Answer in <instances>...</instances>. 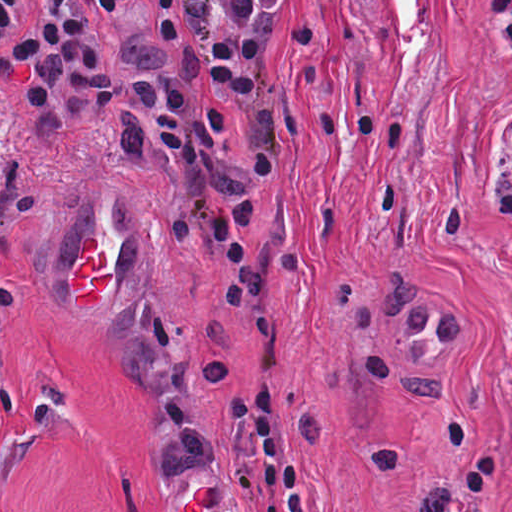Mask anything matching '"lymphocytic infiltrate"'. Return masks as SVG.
<instances>
[{
  "label": "lymphocytic infiltrate",
  "instance_id": "f902f5d3",
  "mask_svg": "<svg viewBox=\"0 0 512 512\" xmlns=\"http://www.w3.org/2000/svg\"><path fill=\"white\" fill-rule=\"evenodd\" d=\"M17 3L0 0V39ZM43 4L34 35L0 59V91L23 90L42 140L114 127L130 161L164 175L168 231L224 274L197 356L200 379H222L250 307L284 263L265 127L289 0ZM483 13L495 54L512 66V0H483ZM495 210L512 240V183ZM228 402L260 477L289 465L283 410L266 377Z\"/></svg>",
  "mask_w": 512,
  "mask_h": 512
}]
</instances>
